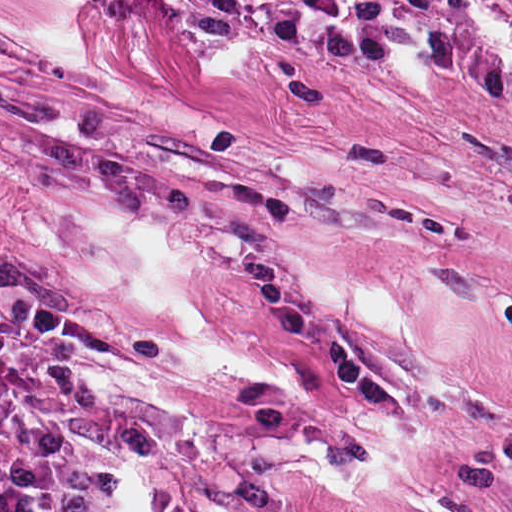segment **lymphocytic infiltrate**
<instances>
[{
	"label": "lymphocytic infiltrate",
	"mask_w": 512,
	"mask_h": 512,
	"mask_svg": "<svg viewBox=\"0 0 512 512\" xmlns=\"http://www.w3.org/2000/svg\"><path fill=\"white\" fill-rule=\"evenodd\" d=\"M369 29H474L512 52V0H313Z\"/></svg>",
	"instance_id": "obj_1"
}]
</instances>
